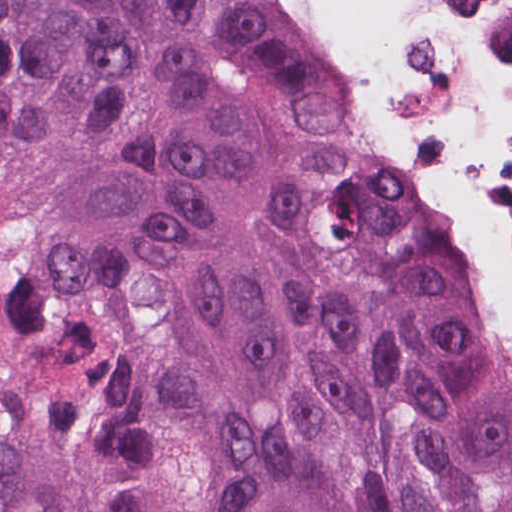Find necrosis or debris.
<instances>
[{
  "label": "necrosis or debris",
  "mask_w": 512,
  "mask_h": 512,
  "mask_svg": "<svg viewBox=\"0 0 512 512\" xmlns=\"http://www.w3.org/2000/svg\"><path fill=\"white\" fill-rule=\"evenodd\" d=\"M512 343V0H290Z\"/></svg>",
  "instance_id": "obj_1"
}]
</instances>
